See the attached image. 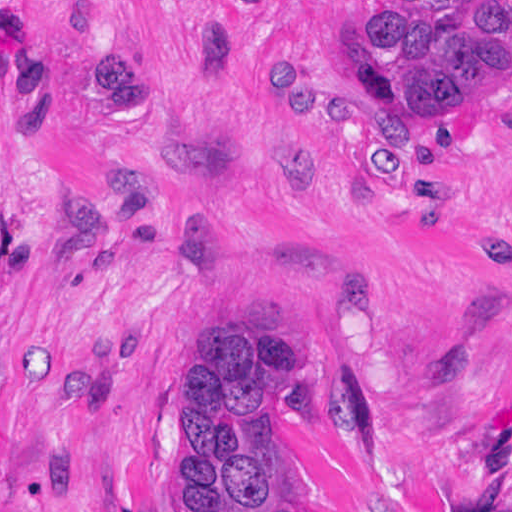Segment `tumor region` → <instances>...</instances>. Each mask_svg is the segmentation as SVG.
Here are the masks:
<instances>
[{"label": "tumor region", "instance_id": "1", "mask_svg": "<svg viewBox=\"0 0 512 512\" xmlns=\"http://www.w3.org/2000/svg\"><path fill=\"white\" fill-rule=\"evenodd\" d=\"M365 63L380 121L486 103L512 91V0H375ZM83 80L118 126L154 125L158 87L131 41L82 45ZM262 114L292 119V50L259 63ZM259 191L323 187L328 153L293 136L255 157ZM471 255L512 276V228L475 229ZM307 379L305 347L243 314L225 316L194 362L174 409L176 512H303L273 466L274 408Z\"/></svg>", "mask_w": 512, "mask_h": 512}]
</instances>
